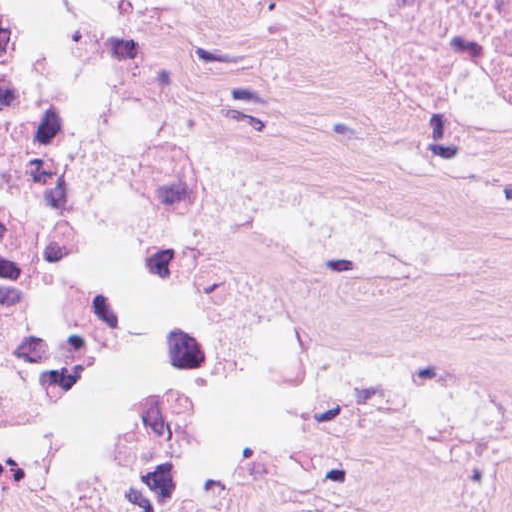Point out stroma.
<instances>
[{"instance_id": "35a3bbf8", "label": "stroma", "mask_w": 512, "mask_h": 512, "mask_svg": "<svg viewBox=\"0 0 512 512\" xmlns=\"http://www.w3.org/2000/svg\"><path fill=\"white\" fill-rule=\"evenodd\" d=\"M173 143L140 485L34 512H512V163L345 0H84Z\"/></svg>"}]
</instances>
